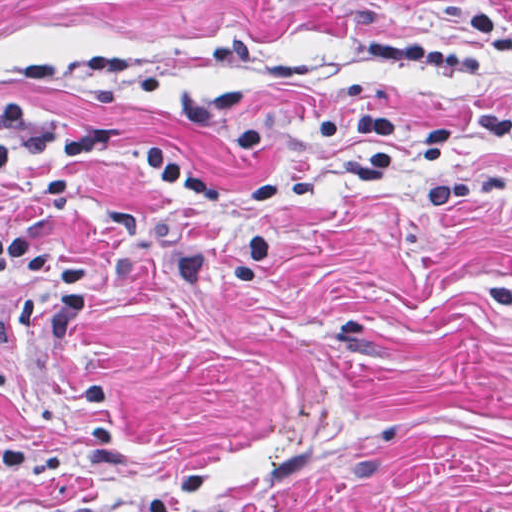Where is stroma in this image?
<instances>
[{
	"label": "stroma",
	"instance_id": "1",
	"mask_svg": "<svg viewBox=\"0 0 512 512\" xmlns=\"http://www.w3.org/2000/svg\"><path fill=\"white\" fill-rule=\"evenodd\" d=\"M0 101L126 140L0 177V512H512V0H0ZM367 108L451 156L366 176ZM147 149L323 192L233 203L267 272L190 287L243 234Z\"/></svg>",
	"mask_w": 512,
	"mask_h": 512
}]
</instances>
